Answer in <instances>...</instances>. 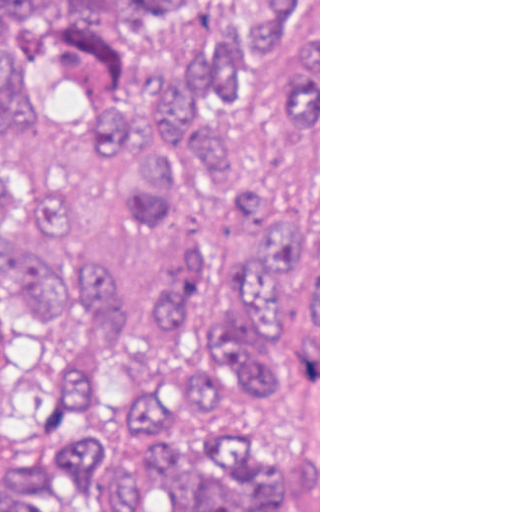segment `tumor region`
Instances as JSON below:
<instances>
[{"label": "tumor region", "mask_w": 512, "mask_h": 512, "mask_svg": "<svg viewBox=\"0 0 512 512\" xmlns=\"http://www.w3.org/2000/svg\"><path fill=\"white\" fill-rule=\"evenodd\" d=\"M0 289L73 416L158 372L0 512H318V0H0ZM222 375L302 403L288 461L222 415L187 477L156 430Z\"/></svg>", "instance_id": "1"}]
</instances>
